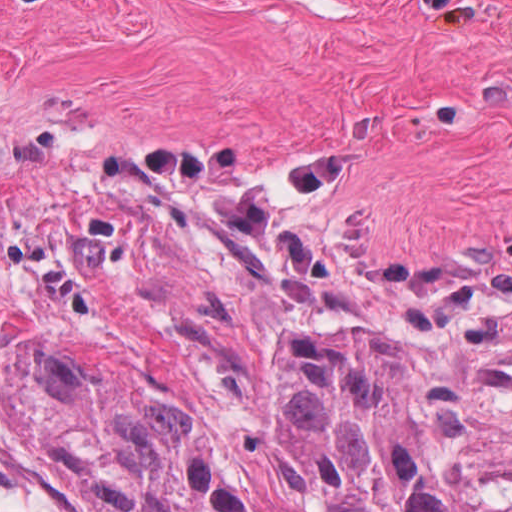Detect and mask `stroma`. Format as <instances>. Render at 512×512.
I'll return each instance as SVG.
<instances>
[{
	"label": "stroma",
	"mask_w": 512,
	"mask_h": 512,
	"mask_svg": "<svg viewBox=\"0 0 512 512\" xmlns=\"http://www.w3.org/2000/svg\"><path fill=\"white\" fill-rule=\"evenodd\" d=\"M441 363L471 480L491 500H512V322Z\"/></svg>",
	"instance_id": "1"
}]
</instances>
